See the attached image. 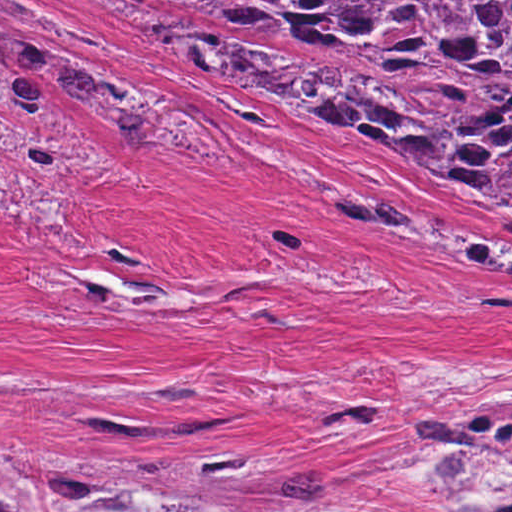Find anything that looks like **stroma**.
<instances>
[{
    "instance_id": "stroma-1",
    "label": "stroma",
    "mask_w": 512,
    "mask_h": 512,
    "mask_svg": "<svg viewBox=\"0 0 512 512\" xmlns=\"http://www.w3.org/2000/svg\"><path fill=\"white\" fill-rule=\"evenodd\" d=\"M14 1L46 22L0 15L147 110L155 134L109 135L24 51L0 49L61 113L0 105V444L191 471L308 424L311 445L256 512L307 471L319 489L298 512H465L415 440L512 378V199L294 82L167 69L146 29L191 43L242 31L394 90L386 61L349 36L181 0ZM357 408L379 420L322 423ZM86 415L231 424L105 434Z\"/></svg>"
}]
</instances>
